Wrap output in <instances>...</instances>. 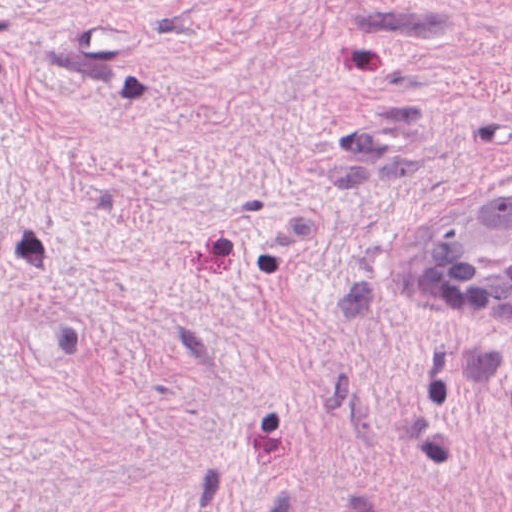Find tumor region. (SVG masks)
Wrapping results in <instances>:
<instances>
[{"instance_id":"tumor-region-1","label":"tumor region","mask_w":512,"mask_h":512,"mask_svg":"<svg viewBox=\"0 0 512 512\" xmlns=\"http://www.w3.org/2000/svg\"><path fill=\"white\" fill-rule=\"evenodd\" d=\"M412 250V263L444 289H512V184L458 203Z\"/></svg>"}]
</instances>
